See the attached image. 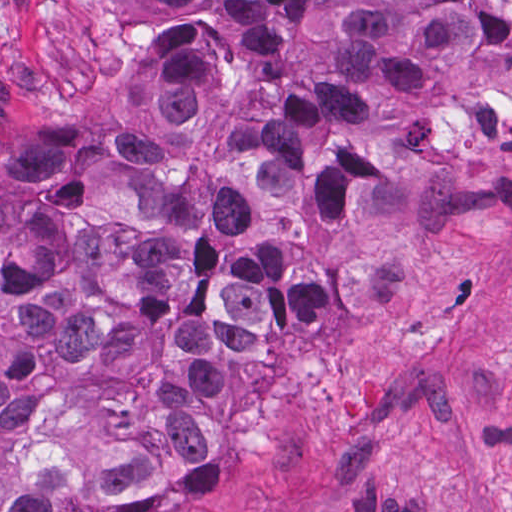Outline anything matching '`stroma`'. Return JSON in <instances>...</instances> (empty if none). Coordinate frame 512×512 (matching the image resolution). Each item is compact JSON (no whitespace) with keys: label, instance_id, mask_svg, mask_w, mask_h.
Listing matches in <instances>:
<instances>
[{"label":"stroma","instance_id":"stroma-1","mask_svg":"<svg viewBox=\"0 0 512 512\" xmlns=\"http://www.w3.org/2000/svg\"><path fill=\"white\" fill-rule=\"evenodd\" d=\"M133 0H0V126L136 125L147 54ZM457 232L391 236L401 302L314 355L227 358L207 466L220 501L149 512H512V93L453 142Z\"/></svg>","mask_w":512,"mask_h":512}]
</instances>
